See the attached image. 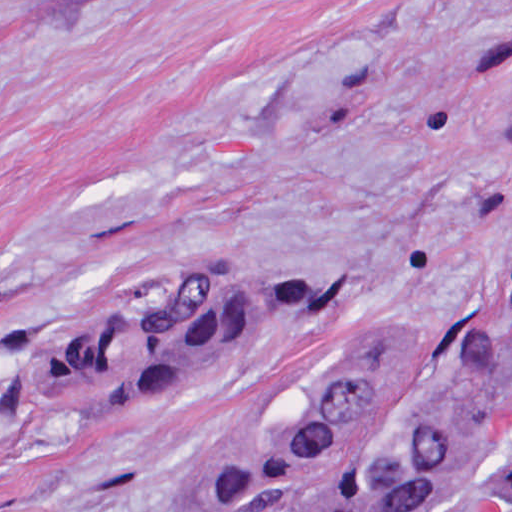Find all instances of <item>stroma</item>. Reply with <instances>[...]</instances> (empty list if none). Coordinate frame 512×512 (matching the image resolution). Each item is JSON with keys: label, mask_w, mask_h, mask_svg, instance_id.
<instances>
[{"label": "stroma", "mask_w": 512, "mask_h": 512, "mask_svg": "<svg viewBox=\"0 0 512 512\" xmlns=\"http://www.w3.org/2000/svg\"><path fill=\"white\" fill-rule=\"evenodd\" d=\"M511 215L512 0H0V512H223L352 338L476 335ZM220 265L336 299L133 416L28 403Z\"/></svg>", "instance_id": "obj_1"}]
</instances>
